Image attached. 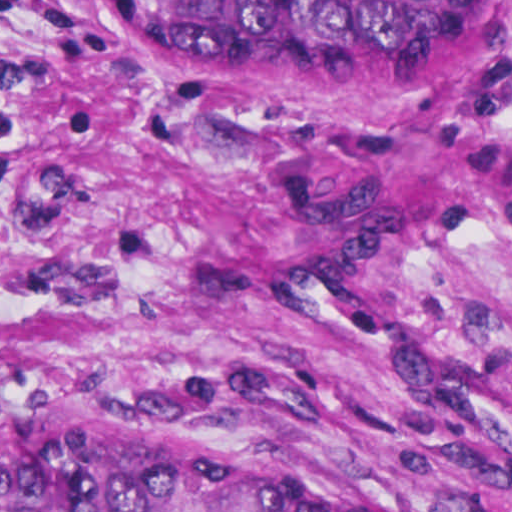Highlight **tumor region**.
<instances>
[{
  "label": "tumor region",
  "mask_w": 512,
  "mask_h": 512,
  "mask_svg": "<svg viewBox=\"0 0 512 512\" xmlns=\"http://www.w3.org/2000/svg\"><path fill=\"white\" fill-rule=\"evenodd\" d=\"M149 36L207 64L390 58L453 43L476 0H158ZM0 512H368L140 451L62 386H0Z\"/></svg>",
  "instance_id": "tumor-region-1"
}]
</instances>
